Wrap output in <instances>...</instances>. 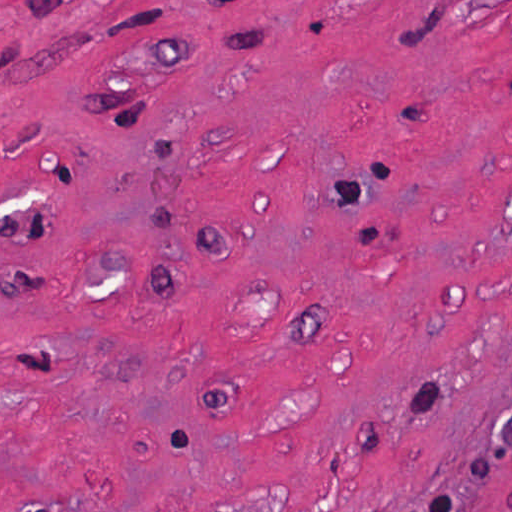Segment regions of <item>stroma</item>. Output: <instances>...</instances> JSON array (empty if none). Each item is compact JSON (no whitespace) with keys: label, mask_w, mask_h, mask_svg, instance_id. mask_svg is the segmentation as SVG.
<instances>
[{"label":"stroma","mask_w":512,"mask_h":512,"mask_svg":"<svg viewBox=\"0 0 512 512\" xmlns=\"http://www.w3.org/2000/svg\"><path fill=\"white\" fill-rule=\"evenodd\" d=\"M512 512V0H0V512Z\"/></svg>","instance_id":"obj_1"}]
</instances>
